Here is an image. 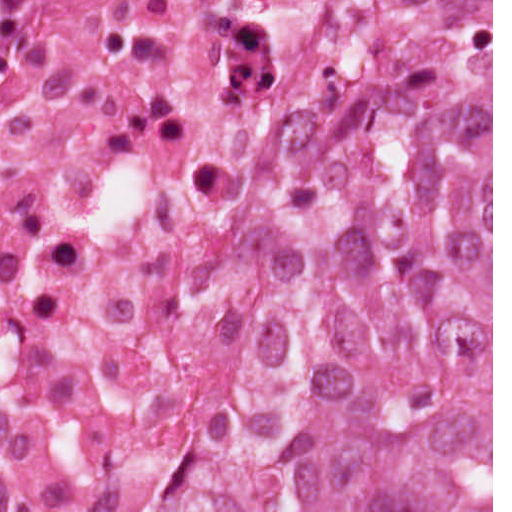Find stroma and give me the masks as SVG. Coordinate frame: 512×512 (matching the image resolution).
I'll use <instances>...</instances> for the list:
<instances>
[{
  "mask_svg": "<svg viewBox=\"0 0 512 512\" xmlns=\"http://www.w3.org/2000/svg\"><path fill=\"white\" fill-rule=\"evenodd\" d=\"M0 1H349V21L367 1H491V512H493V0H0ZM334 51V50H333ZM333 54V52H332ZM331 54V56H332ZM316 86L324 89L328 64Z\"/></svg>",
  "mask_w": 512,
  "mask_h": 512,
  "instance_id": "1",
  "label": "stroma"
}]
</instances>
